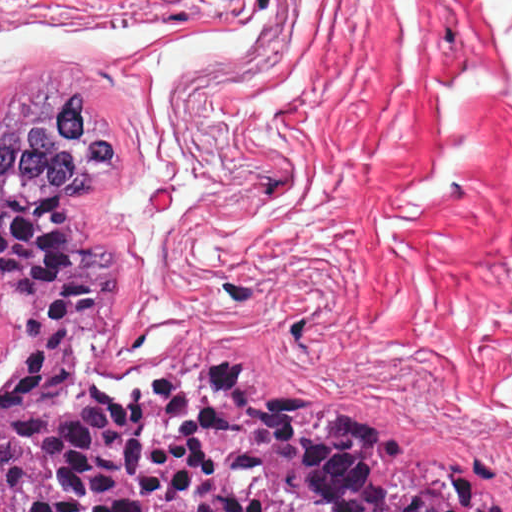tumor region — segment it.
Here are the masks:
<instances>
[{"instance_id":"obj_1","label":"tumor region","mask_w":512,"mask_h":512,"mask_svg":"<svg viewBox=\"0 0 512 512\" xmlns=\"http://www.w3.org/2000/svg\"><path fill=\"white\" fill-rule=\"evenodd\" d=\"M121 148L86 88L0 128V287L19 324L0 512H512L488 457L408 451L257 363L120 380L123 262L95 194Z\"/></svg>"}]
</instances>
